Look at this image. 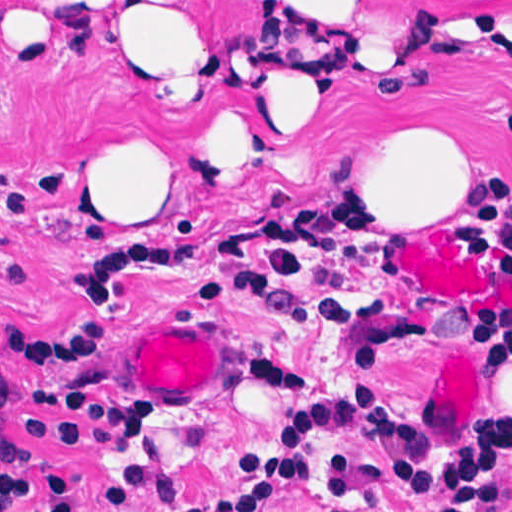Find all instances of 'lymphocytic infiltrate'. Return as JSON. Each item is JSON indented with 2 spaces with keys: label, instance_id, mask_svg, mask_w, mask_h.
Wrapping results in <instances>:
<instances>
[{
  "label": "lymphocytic infiltrate",
  "instance_id": "1",
  "mask_svg": "<svg viewBox=\"0 0 512 512\" xmlns=\"http://www.w3.org/2000/svg\"><path fill=\"white\" fill-rule=\"evenodd\" d=\"M512 135V119L504 122ZM329 200L372 212L385 232L388 254L398 264L400 229L383 221L380 201L357 193V183ZM481 260L512 274V176L495 161V172L469 185L449 208ZM227 228V227H226ZM132 229L100 244L72 251L42 277L30 312L0 308V351L22 358L31 380L0 383V406L31 404L22 424L39 436L94 454H120L141 440L128 411L108 383L105 344L116 332L185 306L198 305L188 287L162 280H135L98 306L78 300L93 255L121 242L205 245L224 229ZM240 354L248 369L267 353L263 333L236 320ZM512 411L475 435L471 459H455L423 445L413 434L398 446L395 492L414 496L424 512H512L507 493V454ZM286 493L263 489L223 512H273ZM139 512H156L167 501L138 496ZM85 500L70 470L37 467L0 429V512H83ZM328 512H341L330 506Z\"/></svg>",
  "mask_w": 512,
  "mask_h": 512
}]
</instances>
